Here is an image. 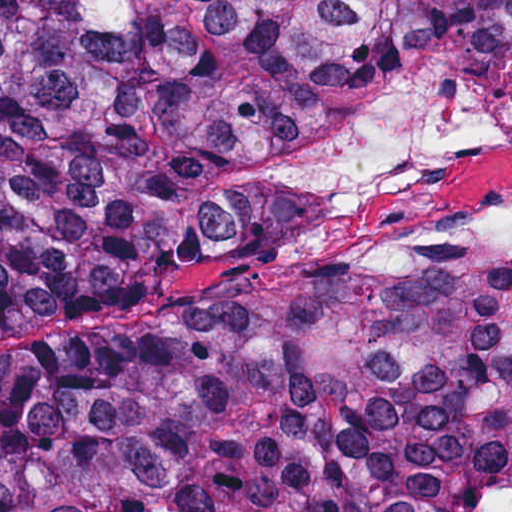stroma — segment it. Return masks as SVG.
<instances>
[{
  "mask_svg": "<svg viewBox=\"0 0 512 512\" xmlns=\"http://www.w3.org/2000/svg\"><path fill=\"white\" fill-rule=\"evenodd\" d=\"M432 79H454L512 103V89L470 73L442 66L418 68L383 97L309 132L280 158L307 174L318 227L275 270L218 280L220 261L176 281H102L3 298L0 356L35 349L59 337L148 325L188 299L275 304L332 279L383 277L425 258L512 256V244H477L468 225L487 207L512 199V147H476L446 165L440 183V224L399 254L374 264L332 265L324 253L352 206L346 191L312 169L305 151L327 126L369 114Z\"/></svg>",
  "mask_w": 512,
  "mask_h": 512,
  "instance_id": "obj_1",
  "label": "stroma"
}]
</instances>
